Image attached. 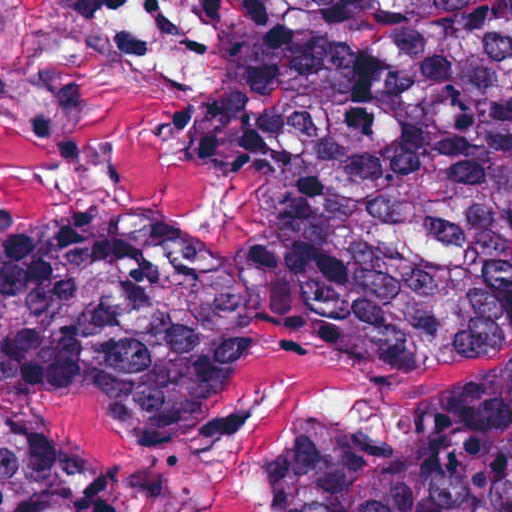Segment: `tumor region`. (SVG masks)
Here are the masks:
<instances>
[{"label":"tumor region","mask_w":512,"mask_h":512,"mask_svg":"<svg viewBox=\"0 0 512 512\" xmlns=\"http://www.w3.org/2000/svg\"><path fill=\"white\" fill-rule=\"evenodd\" d=\"M239 91L281 143L254 244L0 236V512H135L118 475L56 449L104 448L54 427L65 401L191 438L277 351L376 362L512 299V0H239ZM273 488L281 512H512V356L427 394L391 442L295 420Z\"/></svg>","instance_id":"obj_1"}]
</instances>
